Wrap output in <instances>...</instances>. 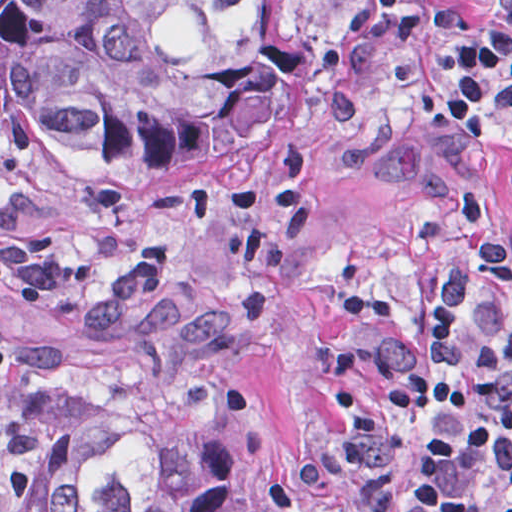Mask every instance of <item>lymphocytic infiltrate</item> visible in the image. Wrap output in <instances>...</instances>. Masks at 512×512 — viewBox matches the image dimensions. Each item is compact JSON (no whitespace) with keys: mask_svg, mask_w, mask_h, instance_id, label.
Returning <instances> with one entry per match:
<instances>
[{"mask_svg":"<svg viewBox=\"0 0 512 512\" xmlns=\"http://www.w3.org/2000/svg\"><path fill=\"white\" fill-rule=\"evenodd\" d=\"M315 1L341 2L316 67L348 130L384 85L372 51L478 23L468 0ZM448 94L476 145L512 118V0L453 59ZM44 201L0 189V231ZM85 209L81 239L0 249V353L14 315L84 284L144 237L140 212ZM287 512H512V231L473 243L380 331L327 402Z\"/></svg>","mask_w":512,"mask_h":512,"instance_id":"obj_1","label":"lymphocytic infiltrate"}]
</instances>
